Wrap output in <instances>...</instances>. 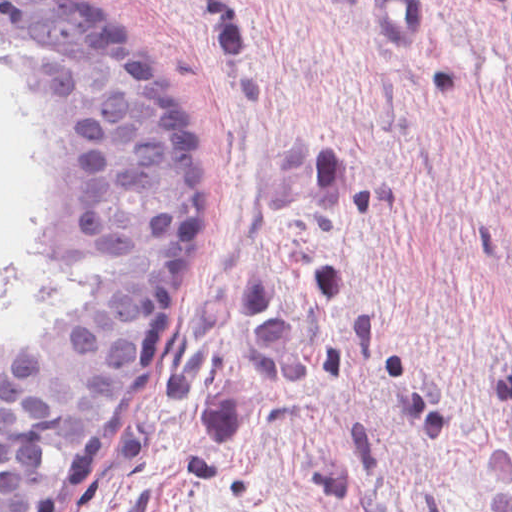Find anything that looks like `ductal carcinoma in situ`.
<instances>
[{"label": "ductal carcinoma in situ", "mask_w": 512, "mask_h": 512, "mask_svg": "<svg viewBox=\"0 0 512 512\" xmlns=\"http://www.w3.org/2000/svg\"><path fill=\"white\" fill-rule=\"evenodd\" d=\"M41 156V251L113 271L31 345L0 344V512H83L145 432L202 308L219 197L191 113L81 0H0Z\"/></svg>", "instance_id": "obj_1"}]
</instances>
